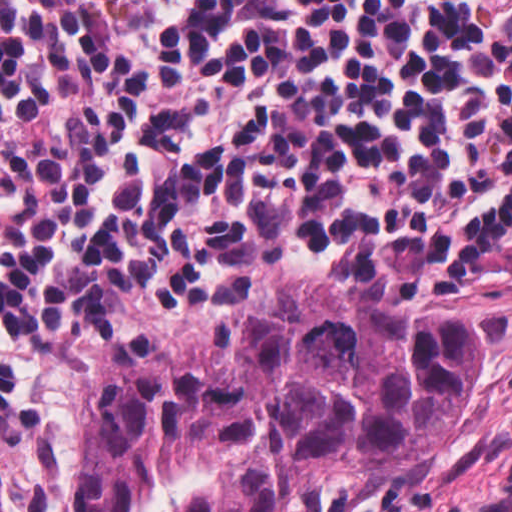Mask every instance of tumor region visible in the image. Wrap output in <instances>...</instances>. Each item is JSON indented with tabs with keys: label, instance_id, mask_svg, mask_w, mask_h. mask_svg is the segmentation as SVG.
I'll return each instance as SVG.
<instances>
[{
	"label": "tumor region",
	"instance_id": "tumor-region-1",
	"mask_svg": "<svg viewBox=\"0 0 512 512\" xmlns=\"http://www.w3.org/2000/svg\"><path fill=\"white\" fill-rule=\"evenodd\" d=\"M477 315L356 293L247 301L227 340L103 365L79 512H280L403 479L467 407Z\"/></svg>",
	"mask_w": 512,
	"mask_h": 512
}]
</instances>
